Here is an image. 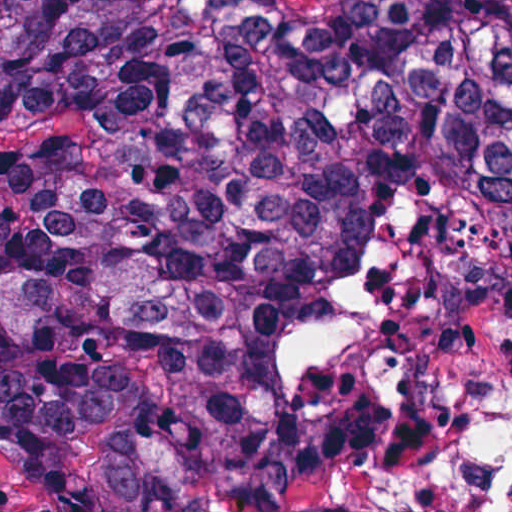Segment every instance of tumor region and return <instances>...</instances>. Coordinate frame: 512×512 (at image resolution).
I'll return each mask as SVG.
<instances>
[{
	"label": "tumor region",
	"instance_id": "e687c5a6",
	"mask_svg": "<svg viewBox=\"0 0 512 512\" xmlns=\"http://www.w3.org/2000/svg\"><path fill=\"white\" fill-rule=\"evenodd\" d=\"M512 322V0H0V462L48 512H381Z\"/></svg>",
	"mask_w": 512,
	"mask_h": 512
}]
</instances>
